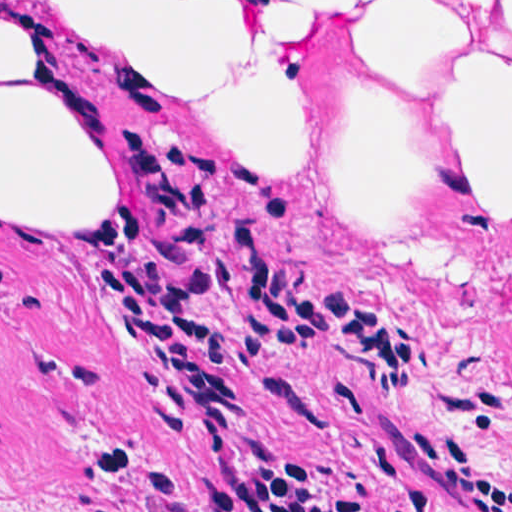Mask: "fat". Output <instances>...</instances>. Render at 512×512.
Wrapping results in <instances>:
<instances>
[{
  "label": "fat",
  "mask_w": 512,
  "mask_h": 512,
  "mask_svg": "<svg viewBox=\"0 0 512 512\" xmlns=\"http://www.w3.org/2000/svg\"><path fill=\"white\" fill-rule=\"evenodd\" d=\"M128 179L110 170L90 103L52 77L39 1L0 2V229L85 241L110 225Z\"/></svg>",
  "instance_id": "53f6f03d"
}]
</instances>
